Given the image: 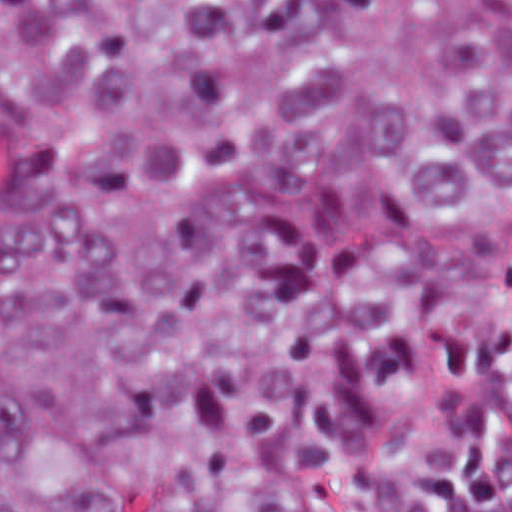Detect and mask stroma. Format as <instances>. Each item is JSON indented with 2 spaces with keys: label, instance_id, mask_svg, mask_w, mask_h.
Masks as SVG:
<instances>
[{
  "label": "stroma",
  "instance_id": "obj_1",
  "mask_svg": "<svg viewBox=\"0 0 512 512\" xmlns=\"http://www.w3.org/2000/svg\"><path fill=\"white\" fill-rule=\"evenodd\" d=\"M0 1H512V0H0ZM497 443L505 457L512 489V418L499 420Z\"/></svg>",
  "mask_w": 512,
  "mask_h": 512
}]
</instances>
